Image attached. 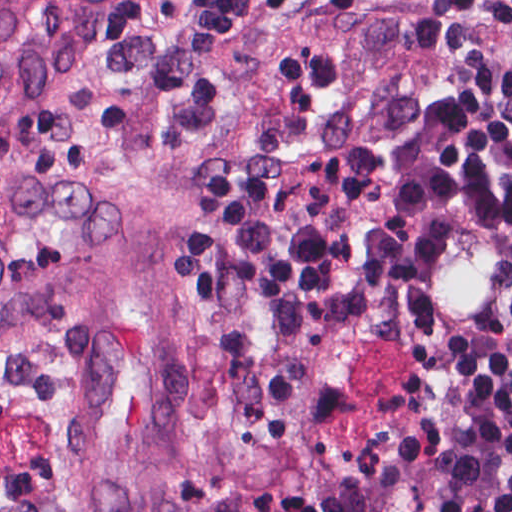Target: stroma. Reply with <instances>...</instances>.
<instances>
[{
  "label": "stroma",
  "instance_id": "obj_1",
  "mask_svg": "<svg viewBox=\"0 0 512 512\" xmlns=\"http://www.w3.org/2000/svg\"><path fill=\"white\" fill-rule=\"evenodd\" d=\"M177 0H0V512H397L455 377L512 321V241L423 225L393 314L239 411L198 306Z\"/></svg>",
  "mask_w": 512,
  "mask_h": 512
}]
</instances>
